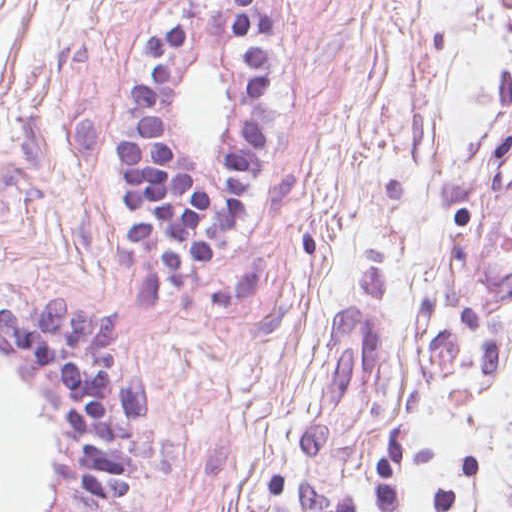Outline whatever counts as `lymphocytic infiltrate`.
I'll return each mask as SVG.
<instances>
[{"label": "lymphocytic infiltrate", "instance_id": "1", "mask_svg": "<svg viewBox=\"0 0 512 512\" xmlns=\"http://www.w3.org/2000/svg\"><path fill=\"white\" fill-rule=\"evenodd\" d=\"M222 1L247 67V93L221 184L190 180L158 129L155 98L191 38L178 23L146 37L150 68L132 81V97L144 115L120 145L124 205L147 213L130 239L136 249L159 254L178 290H200L216 254L241 234L250 189L268 153L260 100L272 76V11L260 0ZM116 336L107 313L75 307L70 297L0 301V348L48 371L79 437V491L69 512H119L139 487L149 382L117 359ZM292 512H357V503L351 494L302 478Z\"/></svg>", "mask_w": 512, "mask_h": 512}]
</instances>
